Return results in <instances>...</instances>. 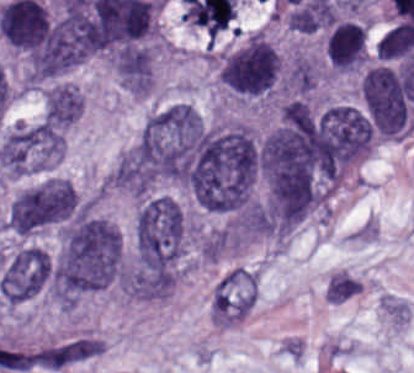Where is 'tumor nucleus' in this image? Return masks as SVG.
<instances>
[{"label":"tumor nucleus","instance_id":"2083b535","mask_svg":"<svg viewBox=\"0 0 414 373\" xmlns=\"http://www.w3.org/2000/svg\"><path fill=\"white\" fill-rule=\"evenodd\" d=\"M324 51L333 70L362 68L367 62V27L356 20H336L325 36Z\"/></svg>","mask_w":414,"mask_h":373},{"label":"tumor nucleus","instance_id":"8643909e","mask_svg":"<svg viewBox=\"0 0 414 373\" xmlns=\"http://www.w3.org/2000/svg\"><path fill=\"white\" fill-rule=\"evenodd\" d=\"M257 168L256 140L247 123L220 122L209 128L188 191L205 210L235 211L251 202Z\"/></svg>","mask_w":414,"mask_h":373},{"label":"tumor nucleus","instance_id":"2cbd58db","mask_svg":"<svg viewBox=\"0 0 414 373\" xmlns=\"http://www.w3.org/2000/svg\"><path fill=\"white\" fill-rule=\"evenodd\" d=\"M281 71L278 49L262 30L247 33L220 56L219 80L246 99L276 91Z\"/></svg>","mask_w":414,"mask_h":373},{"label":"tumor nucleus","instance_id":"8087334f","mask_svg":"<svg viewBox=\"0 0 414 373\" xmlns=\"http://www.w3.org/2000/svg\"><path fill=\"white\" fill-rule=\"evenodd\" d=\"M114 70L122 88L131 96H146L153 84V53L146 45H133L113 58Z\"/></svg>","mask_w":414,"mask_h":373},{"label":"tumor nucleus","instance_id":"2f306a5c","mask_svg":"<svg viewBox=\"0 0 414 373\" xmlns=\"http://www.w3.org/2000/svg\"><path fill=\"white\" fill-rule=\"evenodd\" d=\"M121 239L117 228L96 215L66 224L51 261L57 303L76 306L120 285Z\"/></svg>","mask_w":414,"mask_h":373},{"label":"tumor nucleus","instance_id":"5ab6c2c4","mask_svg":"<svg viewBox=\"0 0 414 373\" xmlns=\"http://www.w3.org/2000/svg\"><path fill=\"white\" fill-rule=\"evenodd\" d=\"M188 238L184 210L168 195L142 200L134 218L136 266L173 269L183 256Z\"/></svg>","mask_w":414,"mask_h":373},{"label":"tumor nucleus","instance_id":"3d1891a8","mask_svg":"<svg viewBox=\"0 0 414 373\" xmlns=\"http://www.w3.org/2000/svg\"><path fill=\"white\" fill-rule=\"evenodd\" d=\"M257 290V275L235 267L223 275L212 295L210 309L215 323L234 324L250 312Z\"/></svg>","mask_w":414,"mask_h":373},{"label":"tumor nucleus","instance_id":"c2bd9aea","mask_svg":"<svg viewBox=\"0 0 414 373\" xmlns=\"http://www.w3.org/2000/svg\"><path fill=\"white\" fill-rule=\"evenodd\" d=\"M84 95L74 83H55L46 89L43 116L62 131L83 112Z\"/></svg>","mask_w":414,"mask_h":373}]
</instances>
